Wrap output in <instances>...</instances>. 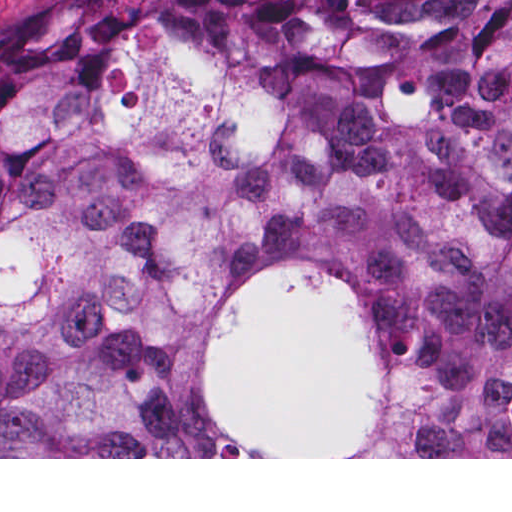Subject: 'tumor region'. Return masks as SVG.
<instances>
[{
  "label": "tumor region",
  "mask_w": 512,
  "mask_h": 512,
  "mask_svg": "<svg viewBox=\"0 0 512 512\" xmlns=\"http://www.w3.org/2000/svg\"><path fill=\"white\" fill-rule=\"evenodd\" d=\"M367 303L384 435L512 457V0L0 18V457H260L194 367L232 288Z\"/></svg>",
  "instance_id": "1"
}]
</instances>
